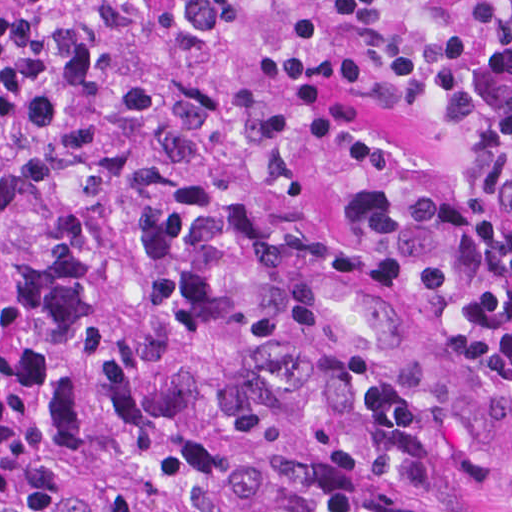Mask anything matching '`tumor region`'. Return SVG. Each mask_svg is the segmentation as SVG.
<instances>
[{
    "label": "tumor region",
    "instance_id": "obj_1",
    "mask_svg": "<svg viewBox=\"0 0 512 512\" xmlns=\"http://www.w3.org/2000/svg\"><path fill=\"white\" fill-rule=\"evenodd\" d=\"M0 512H512V227L334 192L0 233Z\"/></svg>",
    "mask_w": 512,
    "mask_h": 512
}]
</instances>
